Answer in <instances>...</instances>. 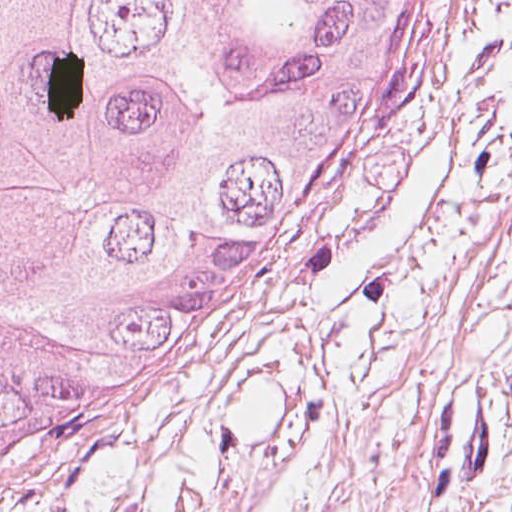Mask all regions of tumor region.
<instances>
[{
  "label": "tumor region",
  "mask_w": 512,
  "mask_h": 512,
  "mask_svg": "<svg viewBox=\"0 0 512 512\" xmlns=\"http://www.w3.org/2000/svg\"><path fill=\"white\" fill-rule=\"evenodd\" d=\"M412 0H0V489L157 397L373 152Z\"/></svg>",
  "instance_id": "1"
}]
</instances>
